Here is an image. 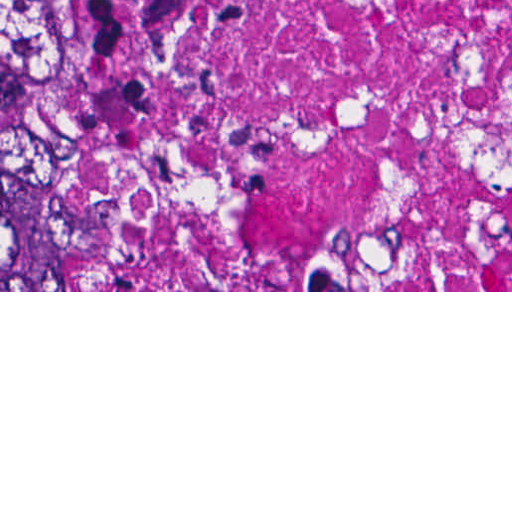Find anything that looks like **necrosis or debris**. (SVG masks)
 <instances>
[{
	"label": "necrosis or debris",
	"instance_id": "4bbe7bcc",
	"mask_svg": "<svg viewBox=\"0 0 512 512\" xmlns=\"http://www.w3.org/2000/svg\"><path fill=\"white\" fill-rule=\"evenodd\" d=\"M148 290H512V0H45Z\"/></svg>",
	"mask_w": 512,
	"mask_h": 512
}]
</instances>
